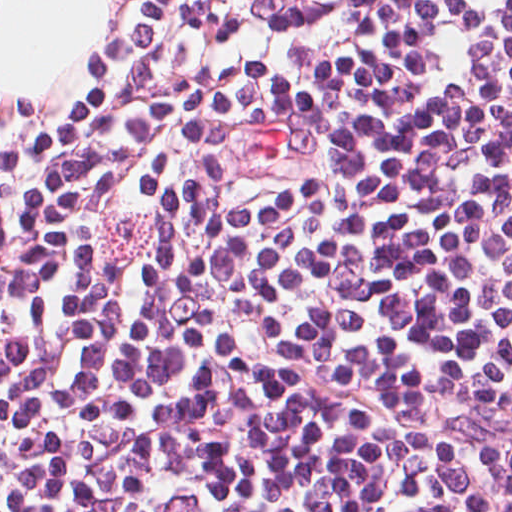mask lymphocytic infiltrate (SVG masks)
Listing matches in <instances>:
<instances>
[{
	"label": "lymphocytic infiltrate",
	"mask_w": 512,
	"mask_h": 512,
	"mask_svg": "<svg viewBox=\"0 0 512 512\" xmlns=\"http://www.w3.org/2000/svg\"><path fill=\"white\" fill-rule=\"evenodd\" d=\"M0 512H512V0H131L0 135Z\"/></svg>",
	"instance_id": "obj_1"
}]
</instances>
